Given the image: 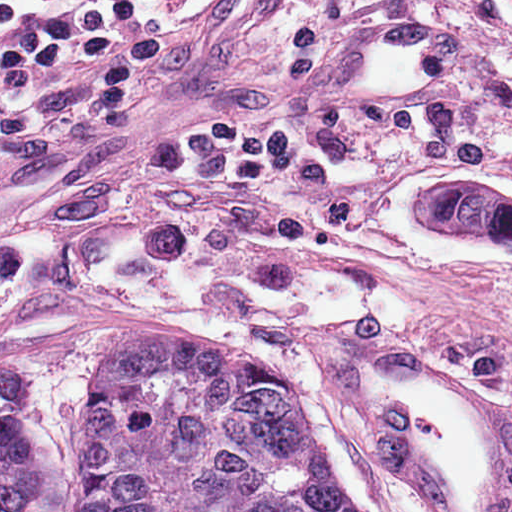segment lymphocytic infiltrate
<instances>
[{"label":"lymphocytic infiltrate","instance_id":"lymphocytic-infiltrate-1","mask_svg":"<svg viewBox=\"0 0 512 512\" xmlns=\"http://www.w3.org/2000/svg\"><path fill=\"white\" fill-rule=\"evenodd\" d=\"M150 94L145 16L91 9L44 23L0 0V131L47 147L133 142Z\"/></svg>","mask_w":512,"mask_h":512}]
</instances>
